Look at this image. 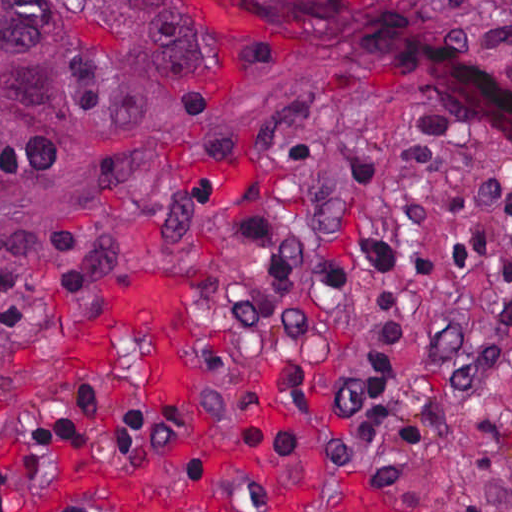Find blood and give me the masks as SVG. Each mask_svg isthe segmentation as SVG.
I'll use <instances>...</instances> for the list:
<instances>
[{"label": "blood", "mask_w": 512, "mask_h": 512, "mask_svg": "<svg viewBox=\"0 0 512 512\" xmlns=\"http://www.w3.org/2000/svg\"><path fill=\"white\" fill-rule=\"evenodd\" d=\"M115 332L153 347L158 357L151 388L194 393L201 378L200 321L192 290L152 270H128L99 287L79 337L64 348L92 368L111 348Z\"/></svg>", "instance_id": "1"}]
</instances>
